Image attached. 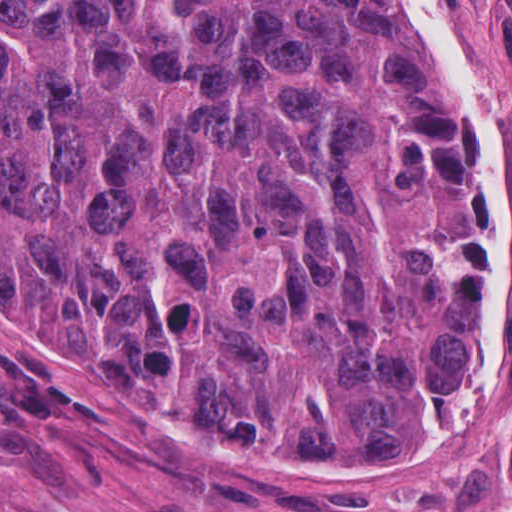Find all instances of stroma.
I'll return each instance as SVG.
<instances>
[{"label":"stroma","mask_w":512,"mask_h":512,"mask_svg":"<svg viewBox=\"0 0 512 512\" xmlns=\"http://www.w3.org/2000/svg\"><path fill=\"white\" fill-rule=\"evenodd\" d=\"M428 1L487 99L509 189L507 331L451 416L382 469L219 447L0 299V512L512 510V0ZM423 86L452 100L479 183L429 59Z\"/></svg>","instance_id":"35a3bbf8"}]
</instances>
